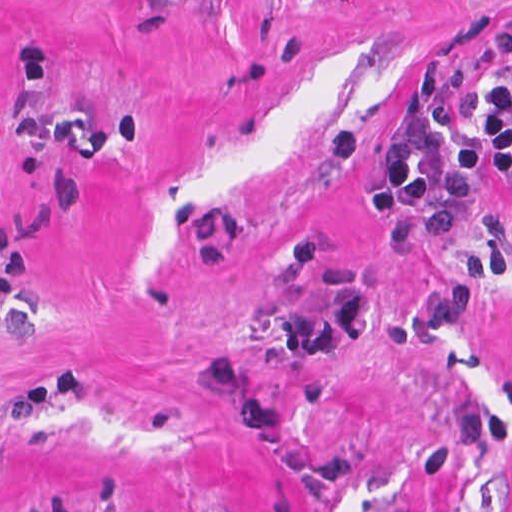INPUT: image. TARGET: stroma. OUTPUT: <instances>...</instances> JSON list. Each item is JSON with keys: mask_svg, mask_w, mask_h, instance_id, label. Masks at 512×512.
<instances>
[{"mask_svg": "<svg viewBox=\"0 0 512 512\" xmlns=\"http://www.w3.org/2000/svg\"><path fill=\"white\" fill-rule=\"evenodd\" d=\"M512 80V0H0V512H512V187L369 218Z\"/></svg>", "mask_w": 512, "mask_h": 512, "instance_id": "35a3bbf8", "label": "stroma"}]
</instances>
